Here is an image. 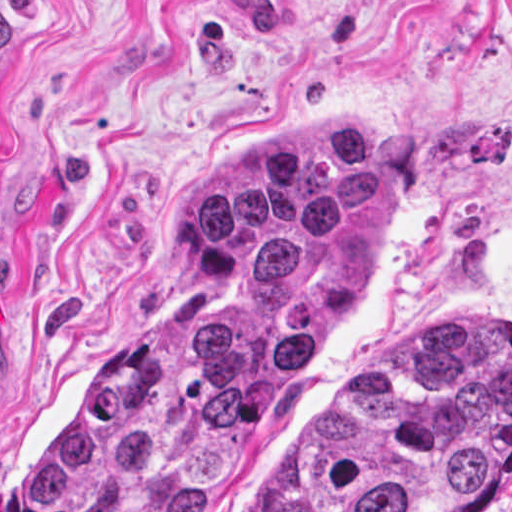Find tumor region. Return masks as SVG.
Listing matches in <instances>:
<instances>
[{"label": "tumor region", "mask_w": 512, "mask_h": 512, "mask_svg": "<svg viewBox=\"0 0 512 512\" xmlns=\"http://www.w3.org/2000/svg\"><path fill=\"white\" fill-rule=\"evenodd\" d=\"M1 111V30H0ZM394 232V163L304 117L200 199L139 323L20 469L31 512H213ZM512 476V320L435 330L341 398L242 512H479Z\"/></svg>", "instance_id": "tumor-region-1"}]
</instances>
